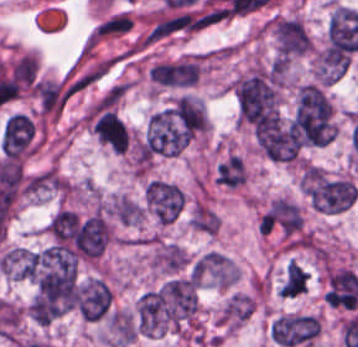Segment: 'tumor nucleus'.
Wrapping results in <instances>:
<instances>
[{
  "label": "tumor nucleus",
  "instance_id": "2f306a5c",
  "mask_svg": "<svg viewBox=\"0 0 358 347\" xmlns=\"http://www.w3.org/2000/svg\"><path fill=\"white\" fill-rule=\"evenodd\" d=\"M268 27L278 59H289L310 50V35L299 19L278 16L271 18Z\"/></svg>",
  "mask_w": 358,
  "mask_h": 347
},
{
  "label": "tumor nucleus",
  "instance_id": "8643909e",
  "mask_svg": "<svg viewBox=\"0 0 358 347\" xmlns=\"http://www.w3.org/2000/svg\"><path fill=\"white\" fill-rule=\"evenodd\" d=\"M143 203L159 224H170L182 210L185 195L180 187L170 182L150 179L145 184Z\"/></svg>",
  "mask_w": 358,
  "mask_h": 347
},
{
  "label": "tumor nucleus",
  "instance_id": "5ab6c2c4",
  "mask_svg": "<svg viewBox=\"0 0 358 347\" xmlns=\"http://www.w3.org/2000/svg\"><path fill=\"white\" fill-rule=\"evenodd\" d=\"M303 225L298 204L288 198H274L258 219L262 234L294 238Z\"/></svg>",
  "mask_w": 358,
  "mask_h": 347
},
{
  "label": "tumor nucleus",
  "instance_id": "2cbd58db",
  "mask_svg": "<svg viewBox=\"0 0 358 347\" xmlns=\"http://www.w3.org/2000/svg\"><path fill=\"white\" fill-rule=\"evenodd\" d=\"M92 133L111 152L123 154L128 149V128L116 112L105 105L93 109Z\"/></svg>",
  "mask_w": 358,
  "mask_h": 347
},
{
  "label": "tumor nucleus",
  "instance_id": "3d1891a8",
  "mask_svg": "<svg viewBox=\"0 0 358 347\" xmlns=\"http://www.w3.org/2000/svg\"><path fill=\"white\" fill-rule=\"evenodd\" d=\"M190 272L197 281L215 287L227 288L234 283V268L230 258L214 251L197 257Z\"/></svg>",
  "mask_w": 358,
  "mask_h": 347
},
{
  "label": "tumor nucleus",
  "instance_id": "2083b535",
  "mask_svg": "<svg viewBox=\"0 0 358 347\" xmlns=\"http://www.w3.org/2000/svg\"><path fill=\"white\" fill-rule=\"evenodd\" d=\"M149 80L158 87H190V59L175 58L151 64Z\"/></svg>",
  "mask_w": 358,
  "mask_h": 347
},
{
  "label": "tumor nucleus",
  "instance_id": "8087334f",
  "mask_svg": "<svg viewBox=\"0 0 358 347\" xmlns=\"http://www.w3.org/2000/svg\"><path fill=\"white\" fill-rule=\"evenodd\" d=\"M253 309L249 293L236 292L226 301L216 320L218 324L236 328L252 315Z\"/></svg>",
  "mask_w": 358,
  "mask_h": 347
},
{
  "label": "tumor nucleus",
  "instance_id": "c2bd9aea",
  "mask_svg": "<svg viewBox=\"0 0 358 347\" xmlns=\"http://www.w3.org/2000/svg\"><path fill=\"white\" fill-rule=\"evenodd\" d=\"M215 180L226 188H239L247 180V168L237 153H230L218 166Z\"/></svg>",
  "mask_w": 358,
  "mask_h": 347
},
{
  "label": "tumor nucleus",
  "instance_id": "feef74b5",
  "mask_svg": "<svg viewBox=\"0 0 358 347\" xmlns=\"http://www.w3.org/2000/svg\"><path fill=\"white\" fill-rule=\"evenodd\" d=\"M187 259L186 252L171 242L158 246L150 257L151 265L161 271L174 273L186 266Z\"/></svg>",
  "mask_w": 358,
  "mask_h": 347
},
{
  "label": "tumor nucleus",
  "instance_id": "3e47fb67",
  "mask_svg": "<svg viewBox=\"0 0 358 347\" xmlns=\"http://www.w3.org/2000/svg\"><path fill=\"white\" fill-rule=\"evenodd\" d=\"M309 273L295 261L287 266L280 289V297H295L305 291Z\"/></svg>",
  "mask_w": 358,
  "mask_h": 347
}]
</instances>
